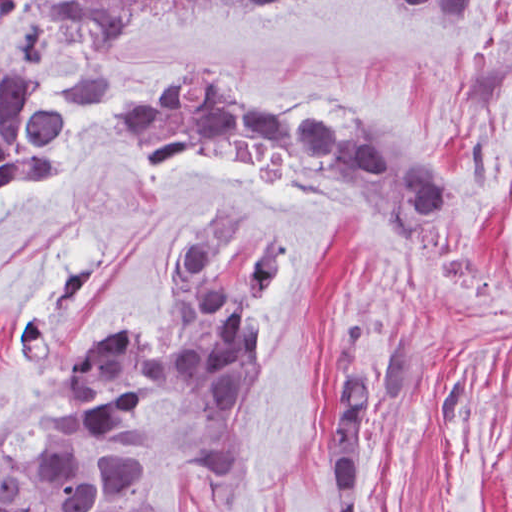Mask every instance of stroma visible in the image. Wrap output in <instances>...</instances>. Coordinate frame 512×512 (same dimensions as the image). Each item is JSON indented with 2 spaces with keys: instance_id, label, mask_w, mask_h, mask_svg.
Here are the masks:
<instances>
[{
  "instance_id": "stroma-1",
  "label": "stroma",
  "mask_w": 512,
  "mask_h": 512,
  "mask_svg": "<svg viewBox=\"0 0 512 512\" xmlns=\"http://www.w3.org/2000/svg\"><path fill=\"white\" fill-rule=\"evenodd\" d=\"M70 2L0 0V60L26 56L45 103L69 98L86 56ZM190 61L223 68L262 112L326 97L407 145L457 195L458 224L403 251L355 208L201 145L141 163L113 114ZM214 199L248 203L288 244L290 270L273 297L269 370L233 427L169 398L140 417L164 512H337L324 393L333 326L351 309L353 367L396 330L419 343L415 389L370 413L360 512H512V0H475L474 22L393 0L135 8L114 36L108 107L72 108L62 174L0 198V442L117 320L159 333L164 264ZM217 443L247 462L227 494L195 479Z\"/></svg>"
}]
</instances>
